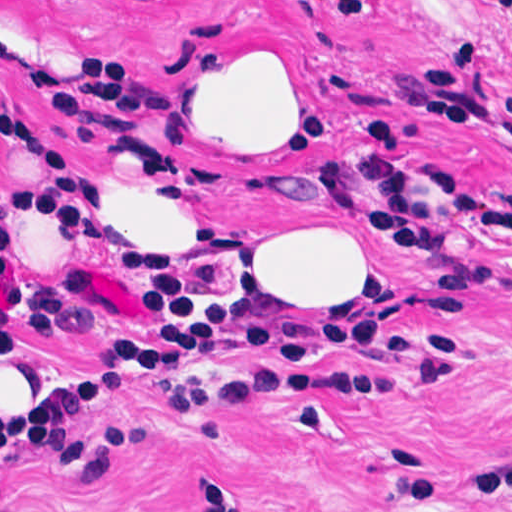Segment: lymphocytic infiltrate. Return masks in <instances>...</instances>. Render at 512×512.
I'll list each match as a JSON object with an SVG mask.
<instances>
[{"mask_svg": "<svg viewBox=\"0 0 512 512\" xmlns=\"http://www.w3.org/2000/svg\"><path fill=\"white\" fill-rule=\"evenodd\" d=\"M0 135L33 158L46 175L40 183L0 177V223L10 214L32 210L71 217L108 228L120 244L144 255L130 246L111 217L99 169L59 148L54 134L0 119ZM243 258L233 239L225 244V258L199 274L165 275L185 299L159 326L141 329L129 343L130 364L121 380L71 386L0 410V446L17 444L49 457L97 496L106 487L117 452L130 443L156 439L149 430L121 423L80 431L78 415L102 404L143 371L164 384L170 406H233L253 385L269 381H348L391 388L382 379L340 371L252 368L206 382L186 375V367L204 361L222 342L274 351L288 359L344 348L365 350L408 364L433 388L463 385L477 371L478 345L437 334H391L376 324L371 309L364 319L341 322L290 308H253L234 295ZM0 275L5 281L15 279V260L1 237Z\"/></svg>", "mask_w": 512, "mask_h": 512, "instance_id": "lymphocytic-infiltrate-1", "label": "lymphocytic infiltrate"}]
</instances>
